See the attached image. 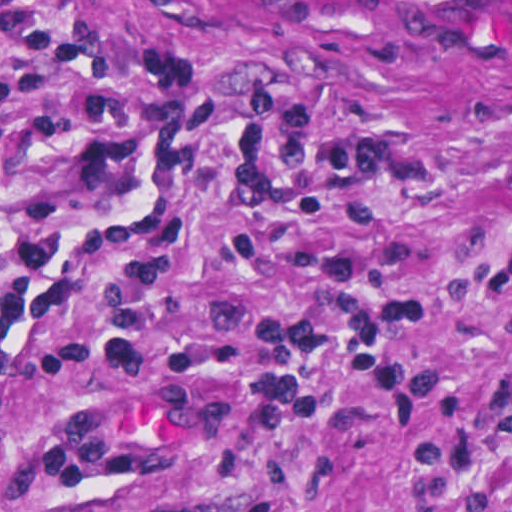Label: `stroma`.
Masks as SVG:
<instances>
[{
	"label": "stroma",
	"mask_w": 512,
	"mask_h": 512,
	"mask_svg": "<svg viewBox=\"0 0 512 512\" xmlns=\"http://www.w3.org/2000/svg\"><path fill=\"white\" fill-rule=\"evenodd\" d=\"M0 512H512V0H0Z\"/></svg>",
	"instance_id": "35a3bbf8"
}]
</instances>
